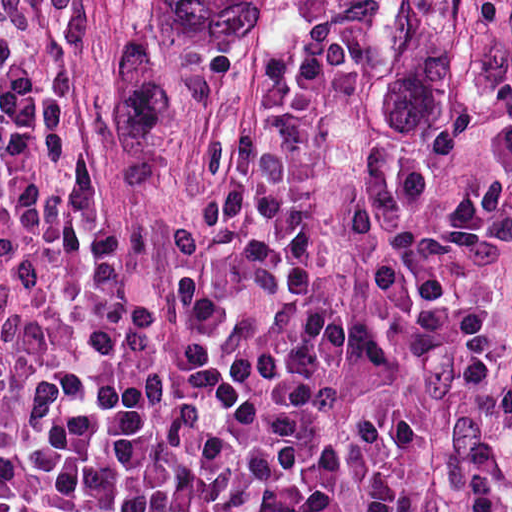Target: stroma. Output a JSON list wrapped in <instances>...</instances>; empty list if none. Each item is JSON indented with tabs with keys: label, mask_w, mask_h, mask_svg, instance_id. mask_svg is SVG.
Wrapping results in <instances>:
<instances>
[{
	"label": "stroma",
	"mask_w": 512,
	"mask_h": 512,
	"mask_svg": "<svg viewBox=\"0 0 512 512\" xmlns=\"http://www.w3.org/2000/svg\"><path fill=\"white\" fill-rule=\"evenodd\" d=\"M79 78L100 186L137 203L175 195L256 79L144 64V0H92ZM355 116L370 195L512 208V0H355ZM511 290L512 229L437 345L424 512L474 511L475 367Z\"/></svg>",
	"instance_id": "35a3bbf8"
}]
</instances>
